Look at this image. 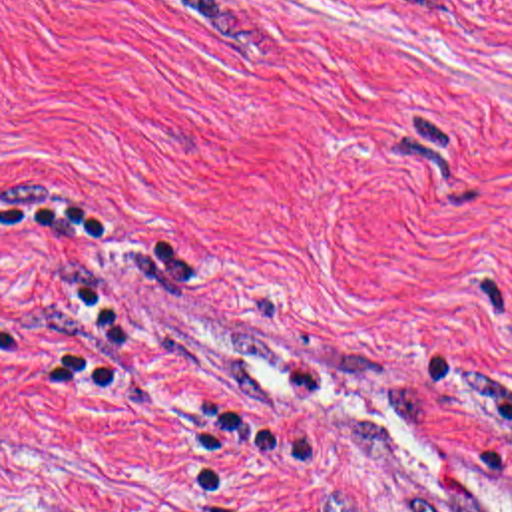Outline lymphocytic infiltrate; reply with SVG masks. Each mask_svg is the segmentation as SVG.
Here are the masks:
<instances>
[{"label": "lymphocytic infiltrate", "mask_w": 512, "mask_h": 512, "mask_svg": "<svg viewBox=\"0 0 512 512\" xmlns=\"http://www.w3.org/2000/svg\"><path fill=\"white\" fill-rule=\"evenodd\" d=\"M2 224L32 238L112 236V218L80 194L2 202ZM137 226L155 236L123 242L125 276L167 284L187 300H199V260L193 250L149 224ZM102 282L106 280L90 272H62L58 284L64 296L92 330L78 346L36 363L32 373L36 393L119 391L123 369L116 349L129 342V324L106 300ZM474 459L488 477H512V399L496 403L480 415L474 429Z\"/></svg>", "instance_id": "obj_1"}]
</instances>
